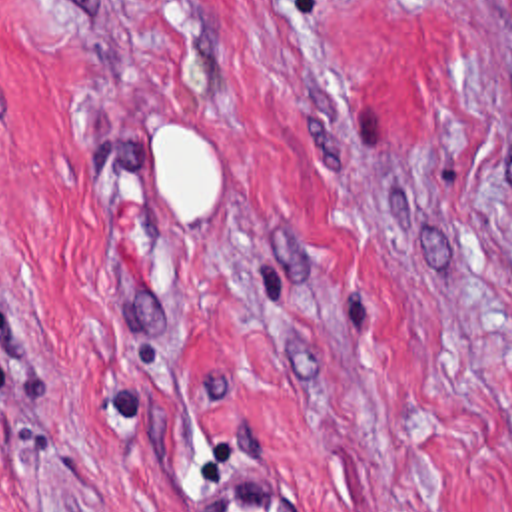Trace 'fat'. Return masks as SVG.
Here are the masks:
<instances>
[{"label": "fat", "mask_w": 512, "mask_h": 512, "mask_svg": "<svg viewBox=\"0 0 512 512\" xmlns=\"http://www.w3.org/2000/svg\"><path fill=\"white\" fill-rule=\"evenodd\" d=\"M175 122H177V118L171 116V120L163 122V124L153 132V138H155L159 132H163L165 128L173 126ZM187 132H189V138H191L193 142H197V144L209 148V154H211V198H209V206H207V210H205V214H203V218H211V214H213V210H215V202H217L219 184H221V148H219L215 142H211L207 136H203L201 132H197V130H193V128H189V126H187Z\"/></svg>", "instance_id": "obj_1"}]
</instances>
